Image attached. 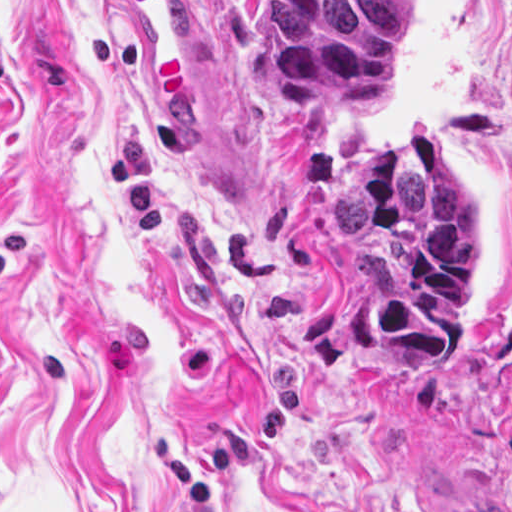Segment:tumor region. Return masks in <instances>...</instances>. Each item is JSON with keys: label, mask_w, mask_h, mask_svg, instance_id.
I'll use <instances>...</instances> for the list:
<instances>
[{"label": "tumor region", "mask_w": 512, "mask_h": 512, "mask_svg": "<svg viewBox=\"0 0 512 512\" xmlns=\"http://www.w3.org/2000/svg\"><path fill=\"white\" fill-rule=\"evenodd\" d=\"M276 30L271 98L287 111L376 115L401 75L414 0H261ZM353 241V343L364 356H448L472 337L478 229L456 168L425 127L331 179Z\"/></svg>", "instance_id": "1"}]
</instances>
